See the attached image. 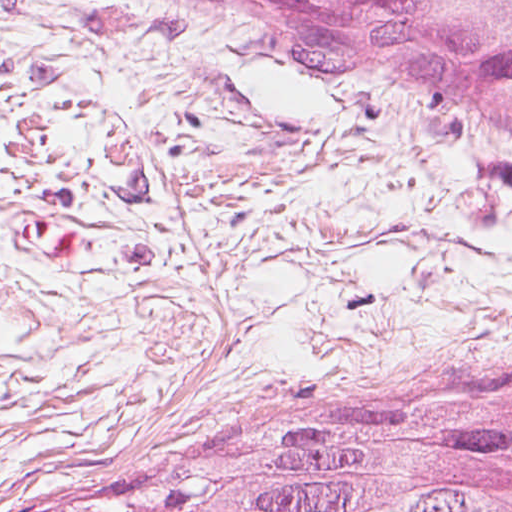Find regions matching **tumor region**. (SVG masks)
Segmentation results:
<instances>
[{
	"label": "tumor region",
	"instance_id": "1",
	"mask_svg": "<svg viewBox=\"0 0 512 512\" xmlns=\"http://www.w3.org/2000/svg\"><path fill=\"white\" fill-rule=\"evenodd\" d=\"M290 55L442 91L512 140V0H208ZM49 512H512V396L358 439L194 457Z\"/></svg>",
	"mask_w": 512,
	"mask_h": 512
}]
</instances>
